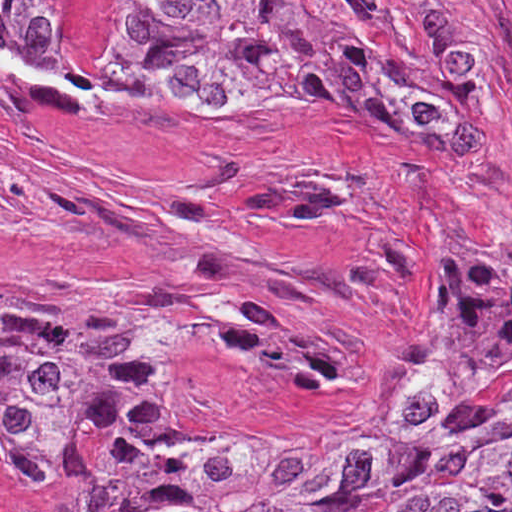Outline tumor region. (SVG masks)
Listing matches in <instances>:
<instances>
[{
	"label": "tumor region",
	"mask_w": 512,
	"mask_h": 512,
	"mask_svg": "<svg viewBox=\"0 0 512 512\" xmlns=\"http://www.w3.org/2000/svg\"><path fill=\"white\" fill-rule=\"evenodd\" d=\"M49 73L256 114L340 105L479 139L496 88L478 0H0ZM229 293L0 276V455L72 512H512V272L463 241L392 360L362 438L168 402L175 317ZM360 442L345 464L319 453Z\"/></svg>",
	"instance_id": "e687c5a6"
}]
</instances>
